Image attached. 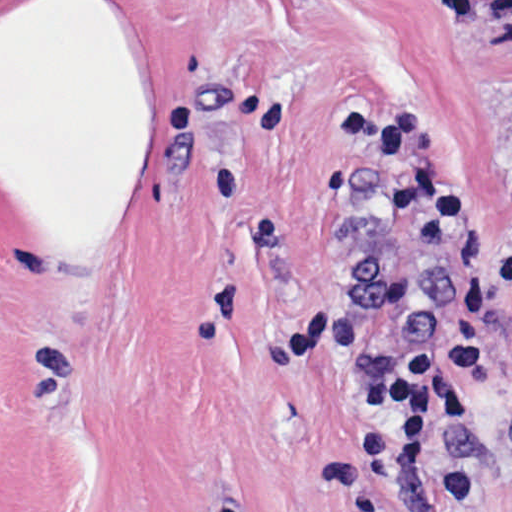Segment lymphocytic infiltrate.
Masks as SVG:
<instances>
[{
    "label": "lymphocytic infiltrate",
    "mask_w": 512,
    "mask_h": 512,
    "mask_svg": "<svg viewBox=\"0 0 512 512\" xmlns=\"http://www.w3.org/2000/svg\"><path fill=\"white\" fill-rule=\"evenodd\" d=\"M325 145L348 154L395 192L415 237L444 270L440 322L395 343L371 365L364 391L390 433V469L432 512H487L491 490L449 454L481 433L469 404L501 381L495 333L512 302V112L507 126L511 223L499 242H475V209L450 175L439 128L421 118L327 116Z\"/></svg>",
    "instance_id": "1"
}]
</instances>
